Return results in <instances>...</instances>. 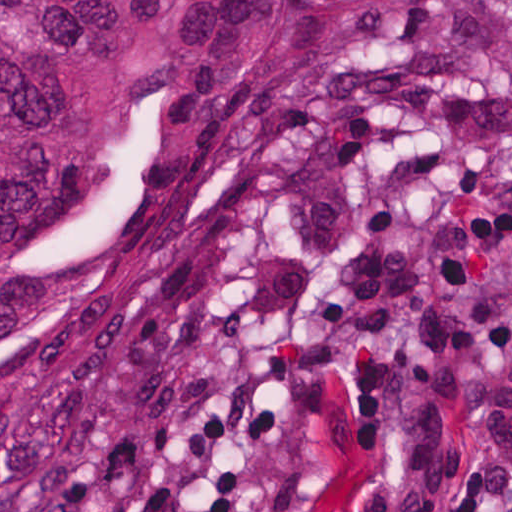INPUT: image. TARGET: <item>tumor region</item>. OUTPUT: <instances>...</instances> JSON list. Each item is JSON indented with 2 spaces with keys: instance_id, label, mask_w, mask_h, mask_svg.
Wrapping results in <instances>:
<instances>
[{
  "instance_id": "1",
  "label": "tumor region",
  "mask_w": 512,
  "mask_h": 512,
  "mask_svg": "<svg viewBox=\"0 0 512 512\" xmlns=\"http://www.w3.org/2000/svg\"><path fill=\"white\" fill-rule=\"evenodd\" d=\"M420 0H1V512L116 404L201 190L392 78Z\"/></svg>"
}]
</instances>
